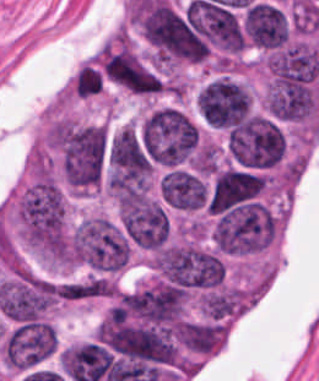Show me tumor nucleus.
Listing matches in <instances>:
<instances>
[{"label":"tumor nucleus","mask_w":319,"mask_h":381,"mask_svg":"<svg viewBox=\"0 0 319 381\" xmlns=\"http://www.w3.org/2000/svg\"><path fill=\"white\" fill-rule=\"evenodd\" d=\"M226 156L235 165L265 169L284 158V133L272 117L256 114L225 131Z\"/></svg>","instance_id":"2"},{"label":"tumor nucleus","mask_w":319,"mask_h":381,"mask_svg":"<svg viewBox=\"0 0 319 381\" xmlns=\"http://www.w3.org/2000/svg\"><path fill=\"white\" fill-rule=\"evenodd\" d=\"M198 109L209 126L229 129L251 113V95L242 84L220 77L198 95Z\"/></svg>","instance_id":"3"},{"label":"tumor nucleus","mask_w":319,"mask_h":381,"mask_svg":"<svg viewBox=\"0 0 319 381\" xmlns=\"http://www.w3.org/2000/svg\"><path fill=\"white\" fill-rule=\"evenodd\" d=\"M129 238L106 216L82 219L69 232L70 263L96 274L115 275L128 260Z\"/></svg>","instance_id":"1"}]
</instances>
